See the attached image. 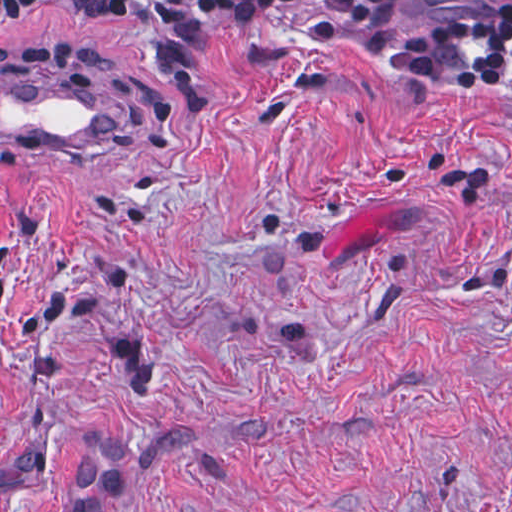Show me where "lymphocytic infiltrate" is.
<instances>
[{
    "label": "lymphocytic infiltrate",
    "instance_id": "f902f5d3",
    "mask_svg": "<svg viewBox=\"0 0 512 512\" xmlns=\"http://www.w3.org/2000/svg\"><path fill=\"white\" fill-rule=\"evenodd\" d=\"M124 1L188 103L210 91L202 55L260 23H282L442 86L512 88V0Z\"/></svg>",
    "mask_w": 512,
    "mask_h": 512
}]
</instances>
